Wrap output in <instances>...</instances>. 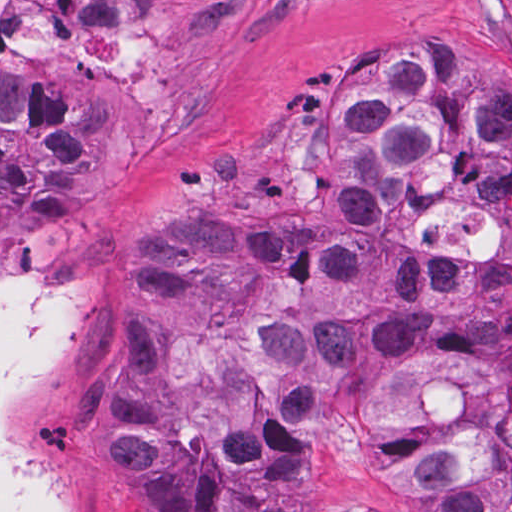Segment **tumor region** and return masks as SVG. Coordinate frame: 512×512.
Masks as SVG:
<instances>
[{
  "label": "tumor region",
  "mask_w": 512,
  "mask_h": 512,
  "mask_svg": "<svg viewBox=\"0 0 512 512\" xmlns=\"http://www.w3.org/2000/svg\"><path fill=\"white\" fill-rule=\"evenodd\" d=\"M487 66L471 38L380 47L139 235L82 400L118 512H512ZM83 122L0 73V243L61 209Z\"/></svg>",
  "instance_id": "obj_1"
}]
</instances>
